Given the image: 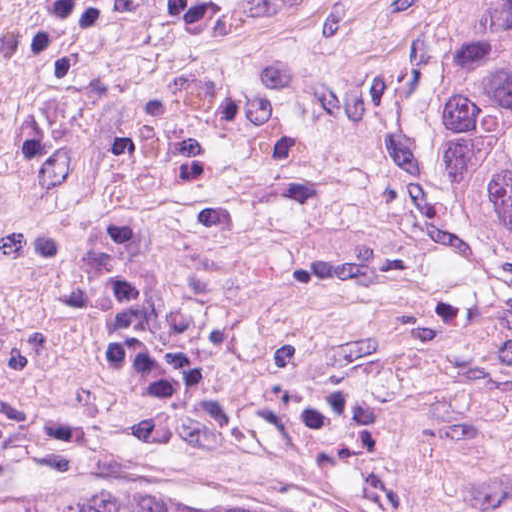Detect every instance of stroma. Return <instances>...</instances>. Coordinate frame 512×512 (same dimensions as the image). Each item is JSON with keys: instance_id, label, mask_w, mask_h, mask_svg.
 Here are the masks:
<instances>
[{"instance_id": "35a3bbf8", "label": "stroma", "mask_w": 512, "mask_h": 512, "mask_svg": "<svg viewBox=\"0 0 512 512\" xmlns=\"http://www.w3.org/2000/svg\"><path fill=\"white\" fill-rule=\"evenodd\" d=\"M452 0H3L0 508L512 512V248L445 170Z\"/></svg>"}]
</instances>
